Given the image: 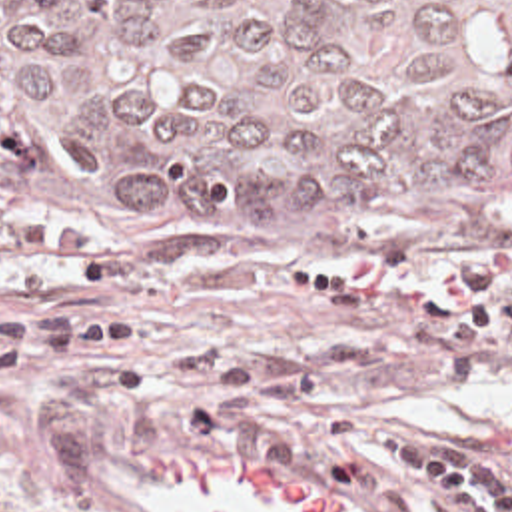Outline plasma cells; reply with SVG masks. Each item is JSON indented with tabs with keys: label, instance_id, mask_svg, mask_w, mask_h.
I'll return each instance as SVG.
<instances>
[{
	"label": "plasma cells",
	"instance_id": "obj_1",
	"mask_svg": "<svg viewBox=\"0 0 512 512\" xmlns=\"http://www.w3.org/2000/svg\"><path fill=\"white\" fill-rule=\"evenodd\" d=\"M161 370L215 384L217 394L191 414L201 446L237 448L265 464H293L312 448L314 434L326 432L368 474L428 486L458 512H512V482L474 456L388 430L354 410H318L295 398L297 386L247 374L219 350L173 352Z\"/></svg>",
	"mask_w": 512,
	"mask_h": 512
}]
</instances>
